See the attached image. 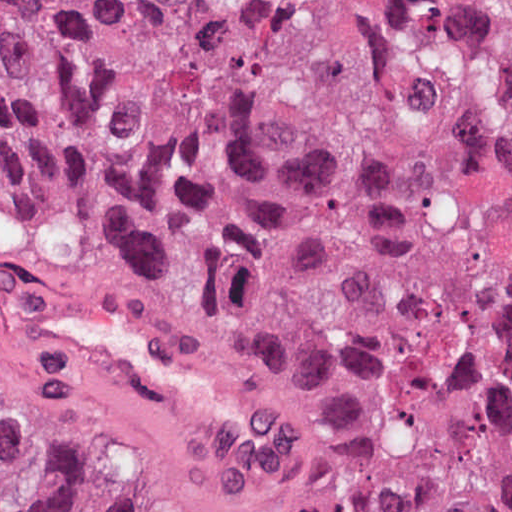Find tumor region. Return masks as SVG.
Returning a JSON list of instances; mask_svg holds the SVG:
<instances>
[{
    "label": "tumor region",
    "instance_id": "obj_1",
    "mask_svg": "<svg viewBox=\"0 0 512 512\" xmlns=\"http://www.w3.org/2000/svg\"><path fill=\"white\" fill-rule=\"evenodd\" d=\"M39 240L238 334L298 425L185 485L3 323ZM0 512H512V0H0Z\"/></svg>",
    "mask_w": 512,
    "mask_h": 512
}]
</instances>
